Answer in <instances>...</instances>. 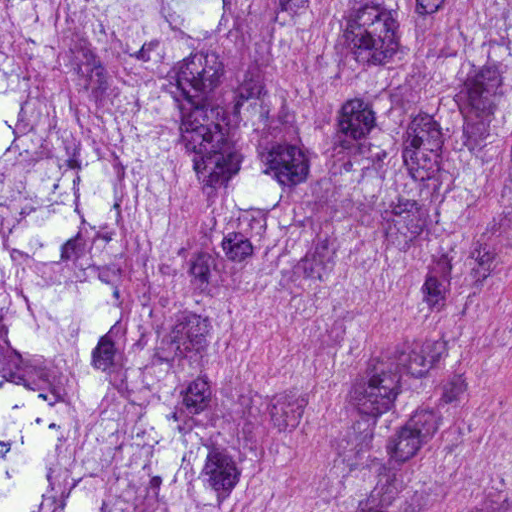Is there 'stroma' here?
<instances>
[{
  "instance_id": "35a3bbf8",
  "label": "stroma",
  "mask_w": 512,
  "mask_h": 512,
  "mask_svg": "<svg viewBox=\"0 0 512 512\" xmlns=\"http://www.w3.org/2000/svg\"><path fill=\"white\" fill-rule=\"evenodd\" d=\"M314 1L261 128L311 221L236 291L223 324L266 425L236 512H351L362 463L512 512V204L479 245L422 257L409 213L337 170L326 132L351 1Z\"/></svg>"
}]
</instances>
